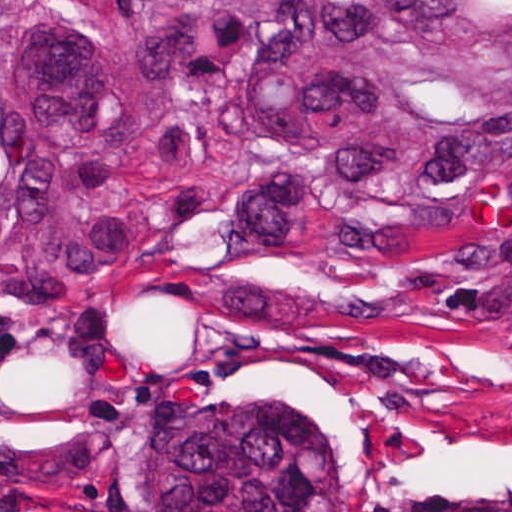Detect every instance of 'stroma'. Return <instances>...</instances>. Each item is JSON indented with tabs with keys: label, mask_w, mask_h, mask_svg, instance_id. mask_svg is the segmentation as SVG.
Returning a JSON list of instances; mask_svg holds the SVG:
<instances>
[{
	"label": "stroma",
	"mask_w": 512,
	"mask_h": 512,
	"mask_svg": "<svg viewBox=\"0 0 512 512\" xmlns=\"http://www.w3.org/2000/svg\"><path fill=\"white\" fill-rule=\"evenodd\" d=\"M504 210L423 246L229 243L221 218L95 298L0 320V512H152V451L194 403L306 414L341 512H512V340L461 331Z\"/></svg>",
	"instance_id": "35a3bbf8"
}]
</instances>
